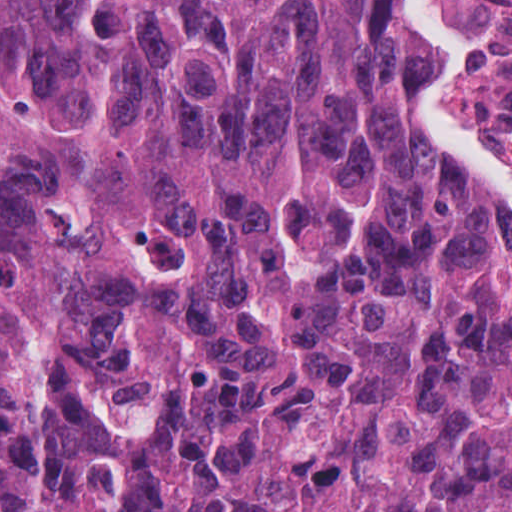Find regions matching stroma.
<instances>
[{
	"label": "stroma",
	"mask_w": 512,
	"mask_h": 512,
	"mask_svg": "<svg viewBox=\"0 0 512 512\" xmlns=\"http://www.w3.org/2000/svg\"><path fill=\"white\" fill-rule=\"evenodd\" d=\"M443 2L472 55L470 68L458 90L465 113L488 145L512 169V0ZM405 4L408 15L419 20L411 6ZM449 63L436 48L424 78L411 88L414 123L438 151L486 190L460 148L432 123L430 93Z\"/></svg>",
	"instance_id": "35a3bbf8"
}]
</instances>
